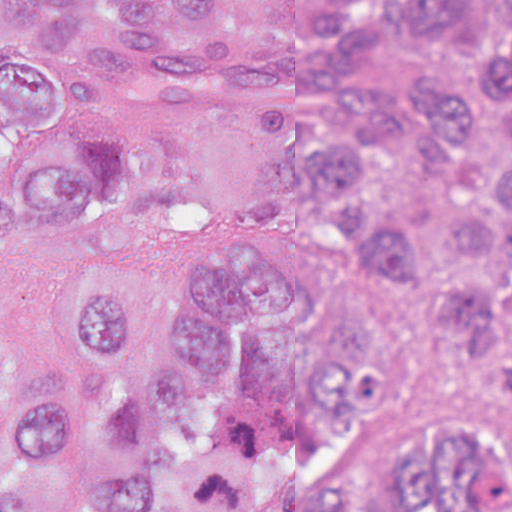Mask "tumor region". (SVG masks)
<instances>
[{
    "label": "tumor region",
    "mask_w": 512,
    "mask_h": 512,
    "mask_svg": "<svg viewBox=\"0 0 512 512\" xmlns=\"http://www.w3.org/2000/svg\"><path fill=\"white\" fill-rule=\"evenodd\" d=\"M173 3L184 30L233 0ZM460 14L465 0H420ZM87 0H0V248L59 252L56 321L76 384L43 403L0 313V512H512V456L475 411L422 419L353 480L352 419L387 380L384 327L333 271L283 245L200 237L155 278L107 252L115 130L83 121L62 39ZM395 32L365 15L317 48L254 54L104 21L99 77L152 106L207 110L288 139L299 194L349 221L370 270L399 284L450 255L504 260L499 289L439 317L488 361L512 357V30L482 72L374 83Z\"/></svg>",
    "instance_id": "obj_1"
}]
</instances>
